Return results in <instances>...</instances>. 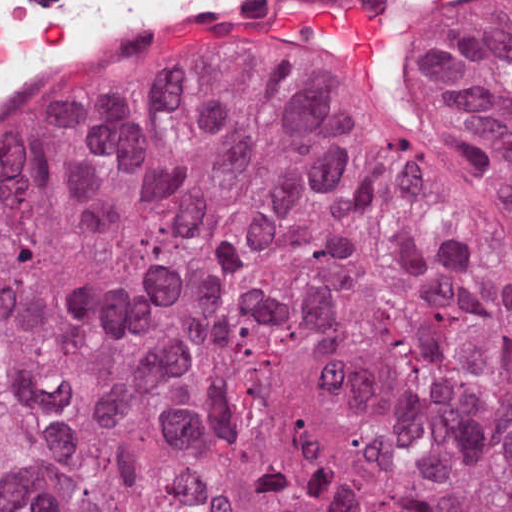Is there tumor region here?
Here are the masks:
<instances>
[{"label": "tumor region", "mask_w": 512, "mask_h": 512, "mask_svg": "<svg viewBox=\"0 0 512 512\" xmlns=\"http://www.w3.org/2000/svg\"><path fill=\"white\" fill-rule=\"evenodd\" d=\"M418 83L512 187V0ZM0 512H512V190L257 48L1 141Z\"/></svg>", "instance_id": "tumor-region-1"}]
</instances>
